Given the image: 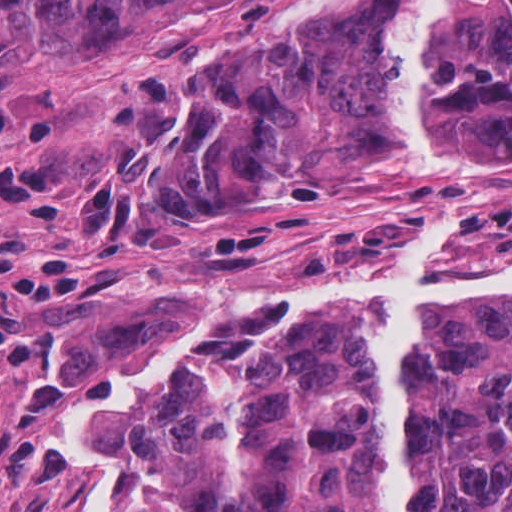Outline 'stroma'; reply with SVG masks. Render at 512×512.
Returning a JSON list of instances; mask_svg holds the SVG:
<instances>
[{
    "mask_svg": "<svg viewBox=\"0 0 512 512\" xmlns=\"http://www.w3.org/2000/svg\"><path fill=\"white\" fill-rule=\"evenodd\" d=\"M385 1L184 0L121 23L98 49L63 55L46 47L40 13L0 0V103L31 104L53 124L50 144L11 146L58 162L73 187L55 220L0 222L108 252L98 286L61 321L49 373L0 385V512H108V484L63 426L86 402L121 403L178 323L224 312L204 299L214 293L376 288L438 219H449L435 256L444 279L512 259V158L429 176L373 152L274 186L232 223L201 222L162 195L167 148L193 124L194 87L226 48L308 45L344 5Z\"/></svg>",
    "mask_w": 512,
    "mask_h": 512,
    "instance_id": "1",
    "label": "stroma"
}]
</instances>
